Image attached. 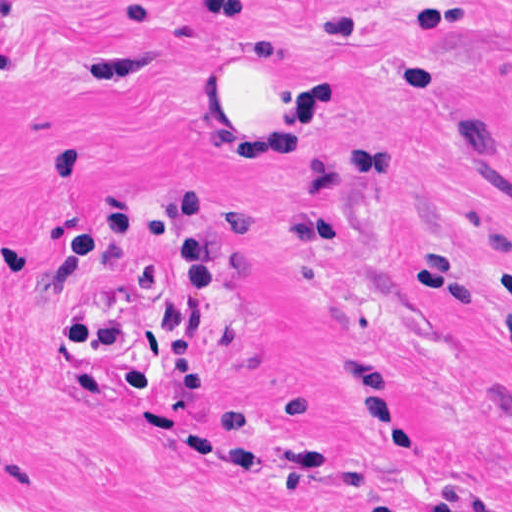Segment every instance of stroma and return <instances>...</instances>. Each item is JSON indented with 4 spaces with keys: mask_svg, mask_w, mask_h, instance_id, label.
Segmentation results:
<instances>
[{
    "mask_svg": "<svg viewBox=\"0 0 512 512\" xmlns=\"http://www.w3.org/2000/svg\"><path fill=\"white\" fill-rule=\"evenodd\" d=\"M0 512H512V0H3ZM320 31V145L237 156L213 60ZM211 200L200 395H130Z\"/></svg>",
    "mask_w": 512,
    "mask_h": 512,
    "instance_id": "obj_1",
    "label": "stroma"
}]
</instances>
